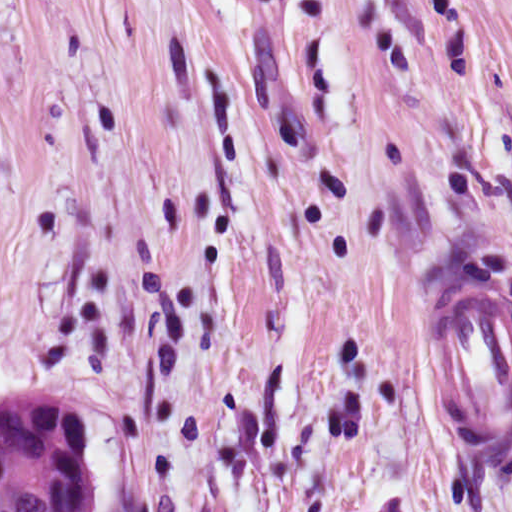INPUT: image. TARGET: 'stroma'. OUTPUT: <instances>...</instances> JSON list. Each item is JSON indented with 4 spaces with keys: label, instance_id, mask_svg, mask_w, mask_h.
<instances>
[{
    "label": "stroma",
    "instance_id": "obj_1",
    "mask_svg": "<svg viewBox=\"0 0 512 512\" xmlns=\"http://www.w3.org/2000/svg\"><path fill=\"white\" fill-rule=\"evenodd\" d=\"M512 299V0H0V388L97 512H512L426 334Z\"/></svg>",
    "mask_w": 512,
    "mask_h": 512
}]
</instances>
